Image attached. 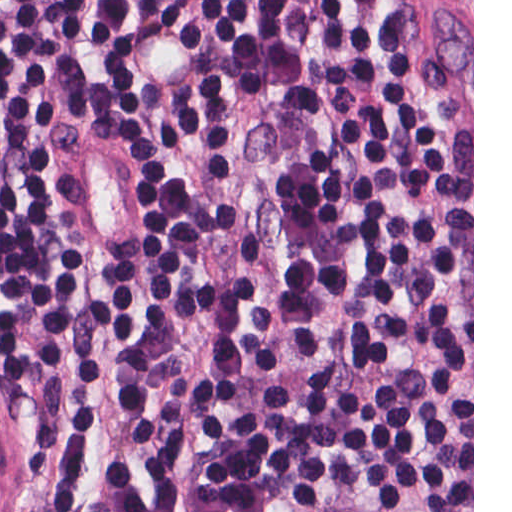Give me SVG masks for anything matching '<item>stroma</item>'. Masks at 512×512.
Masks as SVG:
<instances>
[{"mask_svg": "<svg viewBox=\"0 0 512 512\" xmlns=\"http://www.w3.org/2000/svg\"><path fill=\"white\" fill-rule=\"evenodd\" d=\"M472 72V512H474V0L472 44L454 0H431ZM53 438L29 398L0 372V512H45Z\"/></svg>", "mask_w": 512, "mask_h": 512, "instance_id": "35a3bbf8", "label": "stroma"}]
</instances>
